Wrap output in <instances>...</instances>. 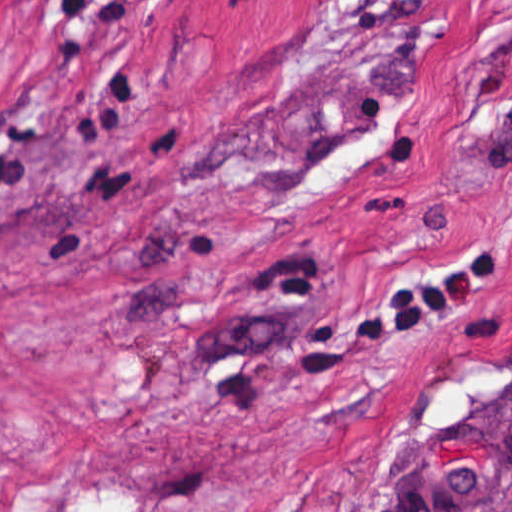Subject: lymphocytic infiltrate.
<instances>
[{"mask_svg": "<svg viewBox=\"0 0 512 512\" xmlns=\"http://www.w3.org/2000/svg\"><path fill=\"white\" fill-rule=\"evenodd\" d=\"M512 218V201L506 221ZM493 236L415 275L395 279L391 296L366 310L352 329L355 346L401 341L502 276Z\"/></svg>", "mask_w": 512, "mask_h": 512, "instance_id": "lymphocytic-infiltrate-1", "label": "lymphocytic infiltrate"}]
</instances>
